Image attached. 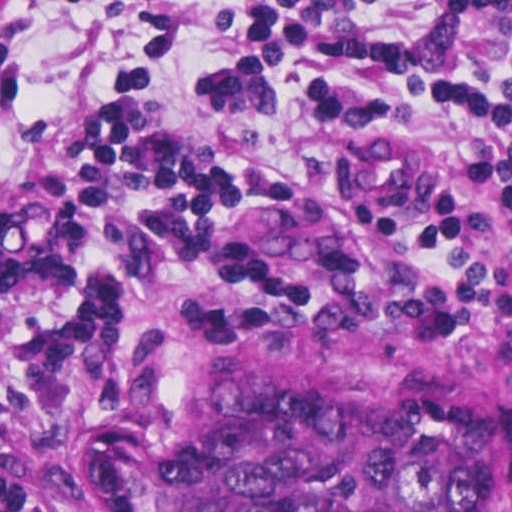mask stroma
I'll return each mask as SVG.
<instances>
[{"label":"stroma","instance_id":"stroma-1","mask_svg":"<svg viewBox=\"0 0 512 512\" xmlns=\"http://www.w3.org/2000/svg\"><path fill=\"white\" fill-rule=\"evenodd\" d=\"M115 4L0 0V208L34 159L43 177L79 159L99 93L133 72L152 78L167 122L232 166H314L297 87L274 115L215 108L203 93L229 37L227 0H188L185 42L159 58H136L111 24ZM223 259L231 286L267 304L129 303L98 323L47 441L43 512H158V451L245 385L367 389L396 403L459 393L502 424L477 512H512V301L382 299L395 276L384 228L347 198L301 186L234 200Z\"/></svg>","mask_w":512,"mask_h":512}]
</instances>
